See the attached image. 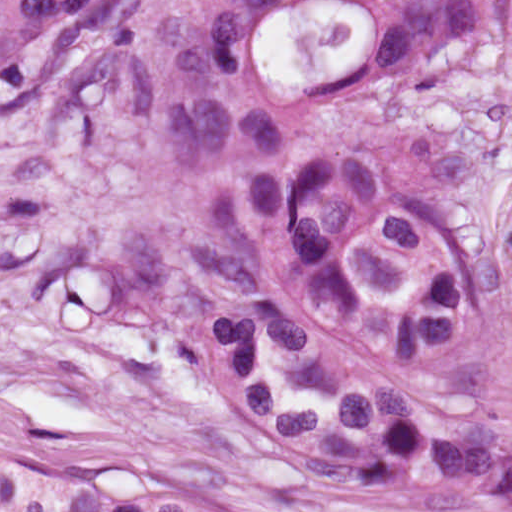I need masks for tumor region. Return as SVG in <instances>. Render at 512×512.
Instances as JSON below:
<instances>
[{
  "label": "tumor region",
  "instance_id": "1",
  "mask_svg": "<svg viewBox=\"0 0 512 512\" xmlns=\"http://www.w3.org/2000/svg\"><path fill=\"white\" fill-rule=\"evenodd\" d=\"M498 0H133L180 125L330 111ZM328 458L512 512V292L445 162L341 153L221 214Z\"/></svg>",
  "mask_w": 512,
  "mask_h": 512
}]
</instances>
